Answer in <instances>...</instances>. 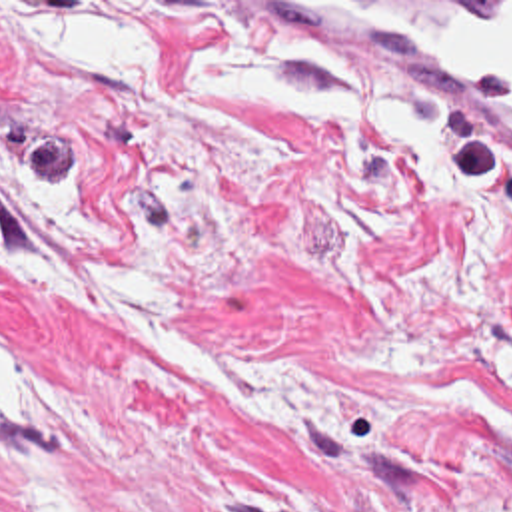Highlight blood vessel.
Returning <instances> with one entry per match:
<instances>
[{
	"instance_id": "blood-vessel-1",
	"label": "blood vessel",
	"mask_w": 512,
	"mask_h": 512,
	"mask_svg": "<svg viewBox=\"0 0 512 512\" xmlns=\"http://www.w3.org/2000/svg\"><path fill=\"white\" fill-rule=\"evenodd\" d=\"M313 62L512 166V2H275Z\"/></svg>"
}]
</instances>
